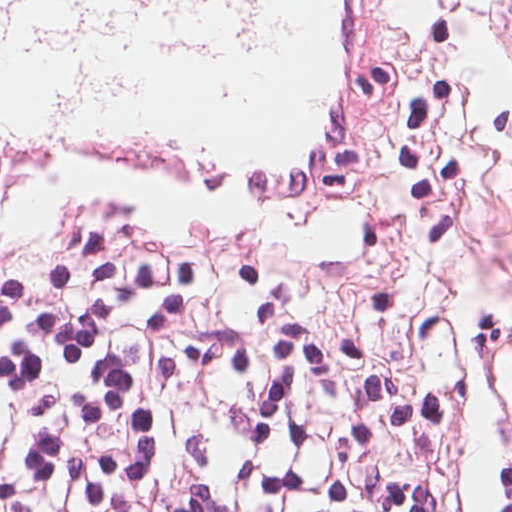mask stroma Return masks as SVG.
<instances>
[{
  "label": "stroma",
  "mask_w": 512,
  "mask_h": 512,
  "mask_svg": "<svg viewBox=\"0 0 512 512\" xmlns=\"http://www.w3.org/2000/svg\"><path fill=\"white\" fill-rule=\"evenodd\" d=\"M392 148L357 197L251 208L184 180L82 171L0 210V281L43 242L211 259L245 309L311 317L404 395L472 371L467 294L512 303V0H378Z\"/></svg>",
  "instance_id": "35a3bbf8"
}]
</instances>
